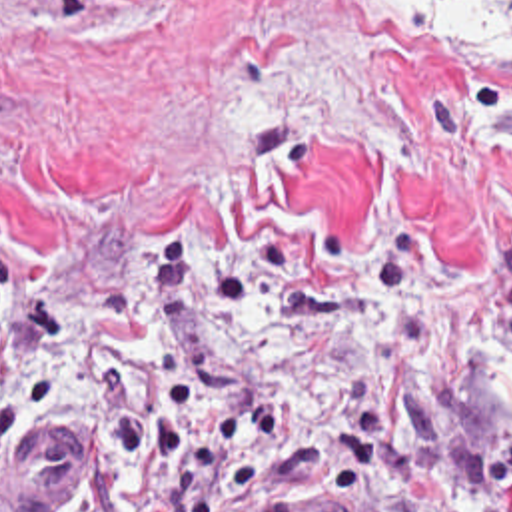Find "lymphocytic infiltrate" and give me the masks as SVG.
Wrapping results in <instances>:
<instances>
[{"instance_id":"lymphocytic-infiltrate-1","label":"lymphocytic infiltrate","mask_w":512,"mask_h":512,"mask_svg":"<svg viewBox=\"0 0 512 512\" xmlns=\"http://www.w3.org/2000/svg\"><path fill=\"white\" fill-rule=\"evenodd\" d=\"M180 308L174 248L148 252L84 318L0 252V476L42 422L62 364L82 354L94 422L72 512H210L290 480L304 460L326 466L343 512H512V430L427 462L367 364L341 368V398L318 384L226 418L170 346Z\"/></svg>"}]
</instances>
